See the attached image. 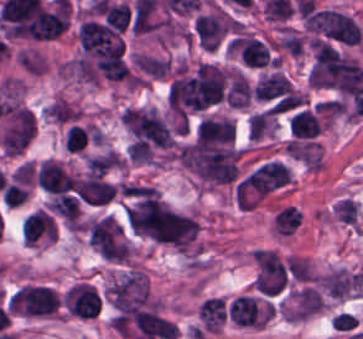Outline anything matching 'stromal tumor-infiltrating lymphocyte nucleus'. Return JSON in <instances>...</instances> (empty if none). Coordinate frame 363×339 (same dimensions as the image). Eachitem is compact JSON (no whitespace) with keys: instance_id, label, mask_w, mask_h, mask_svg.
<instances>
[{"instance_id":"bc302bb0","label":"stromal tumor-infiltrating lymphocyte nucleus","mask_w":363,"mask_h":339,"mask_svg":"<svg viewBox=\"0 0 363 339\" xmlns=\"http://www.w3.org/2000/svg\"><path fill=\"white\" fill-rule=\"evenodd\" d=\"M59 301L55 291L39 285H25L15 292L8 310L29 315L52 314Z\"/></svg>"},{"instance_id":"52c7bb5b","label":"stromal tumor-infiltrating lymphocyte nucleus","mask_w":363,"mask_h":339,"mask_svg":"<svg viewBox=\"0 0 363 339\" xmlns=\"http://www.w3.org/2000/svg\"><path fill=\"white\" fill-rule=\"evenodd\" d=\"M229 47L245 67L263 68L274 65L268 43L256 35L248 33L236 35L231 38Z\"/></svg>"},{"instance_id":"3290ff9b","label":"stromal tumor-infiltrating lymphocyte nucleus","mask_w":363,"mask_h":339,"mask_svg":"<svg viewBox=\"0 0 363 339\" xmlns=\"http://www.w3.org/2000/svg\"><path fill=\"white\" fill-rule=\"evenodd\" d=\"M287 127L291 140L314 141L323 129V119L316 107L301 106L288 113Z\"/></svg>"},{"instance_id":"abfb95fc","label":"stromal tumor-infiltrating lymphocyte nucleus","mask_w":363,"mask_h":339,"mask_svg":"<svg viewBox=\"0 0 363 339\" xmlns=\"http://www.w3.org/2000/svg\"><path fill=\"white\" fill-rule=\"evenodd\" d=\"M66 305L70 314L92 319L99 313L101 298L90 284L77 283L66 292Z\"/></svg>"},{"instance_id":"9ea309e8","label":"stromal tumor-infiltrating lymphocyte nucleus","mask_w":363,"mask_h":339,"mask_svg":"<svg viewBox=\"0 0 363 339\" xmlns=\"http://www.w3.org/2000/svg\"><path fill=\"white\" fill-rule=\"evenodd\" d=\"M133 319L141 339H174L178 335L175 324L155 312L139 310Z\"/></svg>"},{"instance_id":"f3e2335f","label":"stromal tumor-infiltrating lymphocyte nucleus","mask_w":363,"mask_h":339,"mask_svg":"<svg viewBox=\"0 0 363 339\" xmlns=\"http://www.w3.org/2000/svg\"><path fill=\"white\" fill-rule=\"evenodd\" d=\"M38 185L50 193L73 190L76 180L60 161L47 160L39 165Z\"/></svg>"},{"instance_id":"4f13568d","label":"stromal tumor-infiltrating lymphocyte nucleus","mask_w":363,"mask_h":339,"mask_svg":"<svg viewBox=\"0 0 363 339\" xmlns=\"http://www.w3.org/2000/svg\"><path fill=\"white\" fill-rule=\"evenodd\" d=\"M55 236L52 217L40 209L22 222V237L28 244L55 241Z\"/></svg>"},{"instance_id":"2a367800","label":"stromal tumor-infiltrating lymphocyte nucleus","mask_w":363,"mask_h":339,"mask_svg":"<svg viewBox=\"0 0 363 339\" xmlns=\"http://www.w3.org/2000/svg\"><path fill=\"white\" fill-rule=\"evenodd\" d=\"M323 308V299L315 287L304 285L293 295L288 317L292 320H304Z\"/></svg>"},{"instance_id":"4803ca6d","label":"stromal tumor-infiltrating lymphocyte nucleus","mask_w":363,"mask_h":339,"mask_svg":"<svg viewBox=\"0 0 363 339\" xmlns=\"http://www.w3.org/2000/svg\"><path fill=\"white\" fill-rule=\"evenodd\" d=\"M113 184L98 176H88L80 180L77 197L91 205H104L110 201L115 191Z\"/></svg>"},{"instance_id":"4245b91a","label":"stromal tumor-infiltrating lymphocyte nucleus","mask_w":363,"mask_h":339,"mask_svg":"<svg viewBox=\"0 0 363 339\" xmlns=\"http://www.w3.org/2000/svg\"><path fill=\"white\" fill-rule=\"evenodd\" d=\"M200 327L204 331H217L227 319V304L221 297L210 296L198 307Z\"/></svg>"},{"instance_id":"4c9ddf68","label":"stromal tumor-infiltrating lymphocyte nucleus","mask_w":363,"mask_h":339,"mask_svg":"<svg viewBox=\"0 0 363 339\" xmlns=\"http://www.w3.org/2000/svg\"><path fill=\"white\" fill-rule=\"evenodd\" d=\"M233 122L226 118H203L196 133V141L230 144Z\"/></svg>"},{"instance_id":"2761f720","label":"stromal tumor-infiltrating lymphocyte nucleus","mask_w":363,"mask_h":339,"mask_svg":"<svg viewBox=\"0 0 363 339\" xmlns=\"http://www.w3.org/2000/svg\"><path fill=\"white\" fill-rule=\"evenodd\" d=\"M227 314L236 325L262 326L257 305L252 295H239L229 305Z\"/></svg>"},{"instance_id":"3c572f05","label":"stromal tumor-infiltrating lymphocyte nucleus","mask_w":363,"mask_h":339,"mask_svg":"<svg viewBox=\"0 0 363 339\" xmlns=\"http://www.w3.org/2000/svg\"><path fill=\"white\" fill-rule=\"evenodd\" d=\"M195 28L199 45L214 50L225 30L221 21L212 14L196 16Z\"/></svg>"},{"instance_id":"42bb06b2","label":"stromal tumor-infiltrating lymphocyte nucleus","mask_w":363,"mask_h":339,"mask_svg":"<svg viewBox=\"0 0 363 339\" xmlns=\"http://www.w3.org/2000/svg\"><path fill=\"white\" fill-rule=\"evenodd\" d=\"M94 140L90 128L78 122H71L66 126L63 144L69 153H80Z\"/></svg>"},{"instance_id":"9e4306bb","label":"stromal tumor-infiltrating lymphocyte nucleus","mask_w":363,"mask_h":339,"mask_svg":"<svg viewBox=\"0 0 363 339\" xmlns=\"http://www.w3.org/2000/svg\"><path fill=\"white\" fill-rule=\"evenodd\" d=\"M272 223L277 234L290 236L300 224L298 209L293 205L278 209L273 215Z\"/></svg>"},{"instance_id":"04cf8593","label":"stromal tumor-infiltrating lymphocyte nucleus","mask_w":363,"mask_h":339,"mask_svg":"<svg viewBox=\"0 0 363 339\" xmlns=\"http://www.w3.org/2000/svg\"><path fill=\"white\" fill-rule=\"evenodd\" d=\"M131 61L137 67L156 77H163L169 69V60H164L153 56L133 54Z\"/></svg>"}]
</instances>
